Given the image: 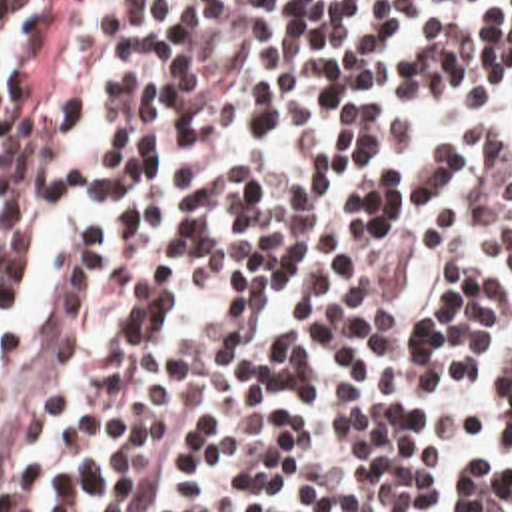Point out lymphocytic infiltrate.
Returning a JSON list of instances; mask_svg holds the SVG:
<instances>
[{
    "instance_id": "1",
    "label": "lymphocytic infiltrate",
    "mask_w": 512,
    "mask_h": 512,
    "mask_svg": "<svg viewBox=\"0 0 512 512\" xmlns=\"http://www.w3.org/2000/svg\"><path fill=\"white\" fill-rule=\"evenodd\" d=\"M0 512H512V0H0Z\"/></svg>"
}]
</instances>
